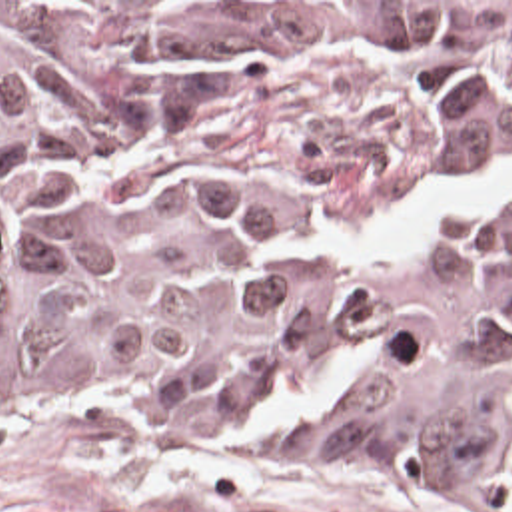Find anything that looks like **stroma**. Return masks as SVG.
<instances>
[{
    "mask_svg": "<svg viewBox=\"0 0 512 512\" xmlns=\"http://www.w3.org/2000/svg\"><path fill=\"white\" fill-rule=\"evenodd\" d=\"M0 2H512V0H0ZM0 512H512V495L265 469L221 451H131L0 435Z\"/></svg>",
    "mask_w": 512,
    "mask_h": 512,
    "instance_id": "1",
    "label": "stroma"
}]
</instances>
